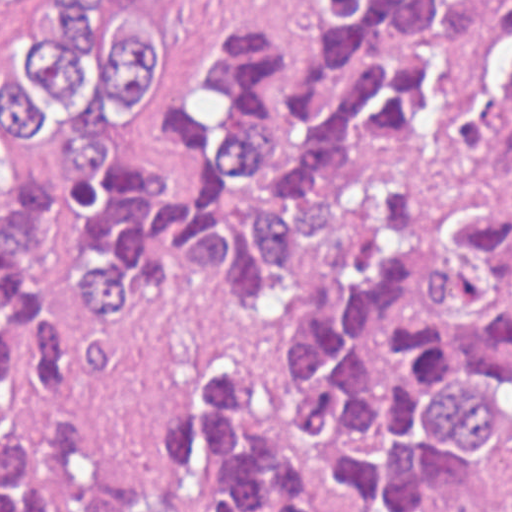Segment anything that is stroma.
<instances>
[{
  "label": "stroma",
  "mask_w": 512,
  "mask_h": 512,
  "mask_svg": "<svg viewBox=\"0 0 512 512\" xmlns=\"http://www.w3.org/2000/svg\"><path fill=\"white\" fill-rule=\"evenodd\" d=\"M172 13V63L162 103L122 148L125 174L163 197L183 186L190 165L163 135V113L187 81L205 39L226 21L247 17L259 38L278 47L287 67V91L301 77L313 0H164ZM498 512H512V443L495 448L484 464ZM0 512H1V0H0ZM336 512H349L339 501ZM424 512H435L426 508Z\"/></svg>",
  "instance_id": "stroma-1"
}]
</instances>
